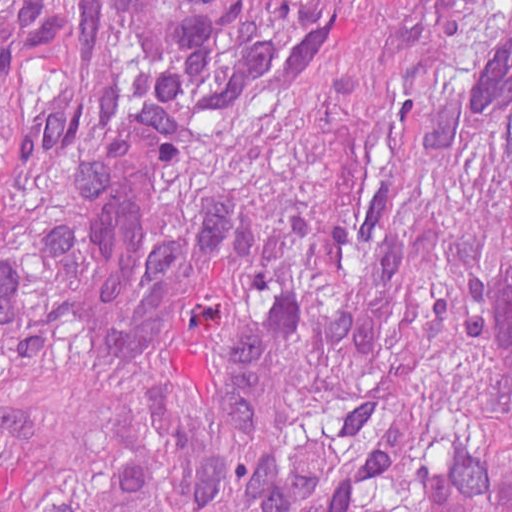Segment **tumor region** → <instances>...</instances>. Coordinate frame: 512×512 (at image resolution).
<instances>
[{"instance_id": "obj_1", "label": "tumor region", "mask_w": 512, "mask_h": 512, "mask_svg": "<svg viewBox=\"0 0 512 512\" xmlns=\"http://www.w3.org/2000/svg\"><path fill=\"white\" fill-rule=\"evenodd\" d=\"M267 219L104 347L69 223ZM0 512H512V0H0Z\"/></svg>"}]
</instances>
